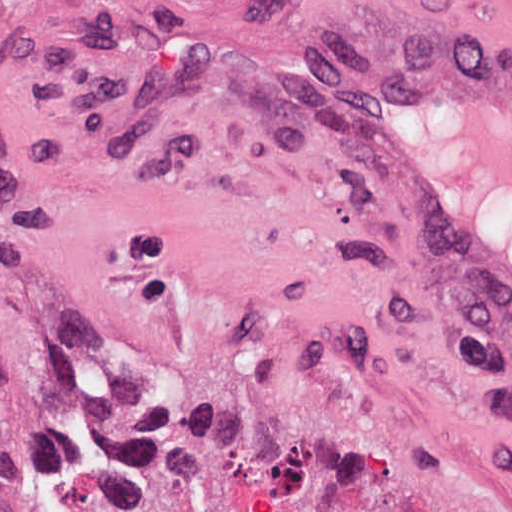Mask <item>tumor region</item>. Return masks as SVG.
<instances>
[{
    "mask_svg": "<svg viewBox=\"0 0 512 512\" xmlns=\"http://www.w3.org/2000/svg\"><path fill=\"white\" fill-rule=\"evenodd\" d=\"M0 512H25V464L15 422L0 402Z\"/></svg>",
    "mask_w": 512,
    "mask_h": 512,
    "instance_id": "e687c5a6",
    "label": "tumor region"
}]
</instances>
